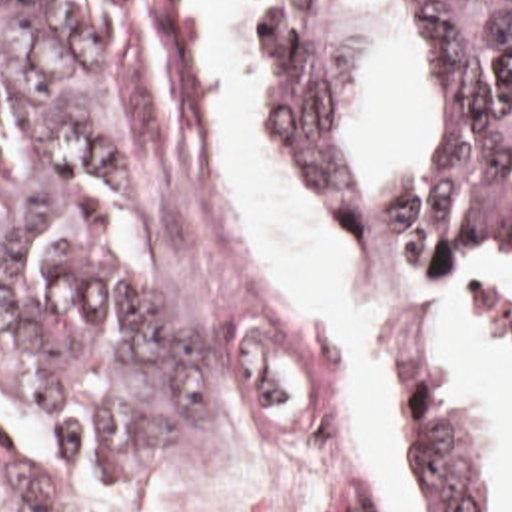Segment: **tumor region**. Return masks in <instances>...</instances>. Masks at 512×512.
<instances>
[{
  "label": "tumor region",
  "mask_w": 512,
  "mask_h": 512,
  "mask_svg": "<svg viewBox=\"0 0 512 512\" xmlns=\"http://www.w3.org/2000/svg\"><path fill=\"white\" fill-rule=\"evenodd\" d=\"M297 165L345 227L371 169L333 105L343 0H251ZM448 85L440 149L379 177L371 253L419 273L512 281V0H422ZM217 357L167 235L135 115L121 0H0V399L103 501L213 445ZM403 512H512L500 461L438 343L397 389Z\"/></svg>",
  "instance_id": "obj_1"
}]
</instances>
